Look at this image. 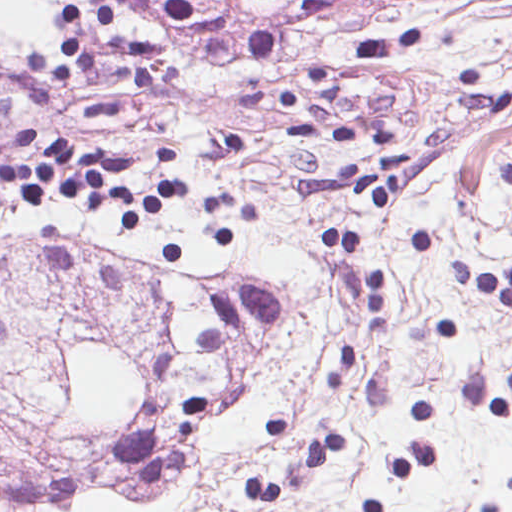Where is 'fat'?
<instances>
[{
    "label": "fat",
    "instance_id": "fat-1",
    "mask_svg": "<svg viewBox=\"0 0 512 512\" xmlns=\"http://www.w3.org/2000/svg\"><path fill=\"white\" fill-rule=\"evenodd\" d=\"M86 0H0V41L21 49L55 42L67 9Z\"/></svg>",
    "mask_w": 512,
    "mask_h": 512
}]
</instances>
